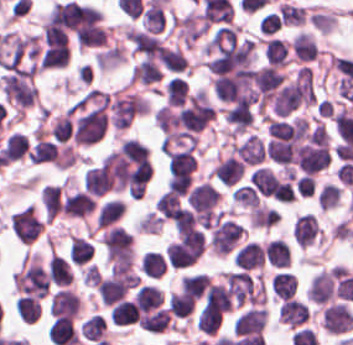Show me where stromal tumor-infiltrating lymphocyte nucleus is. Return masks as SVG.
Returning <instances> with one entry per match:
<instances>
[{
	"label": "stromal tumor-infiltrating lymphocyte nucleus",
	"instance_id": "stromal-tumor-infiltrating-lymphocyte-nucleus-1",
	"mask_svg": "<svg viewBox=\"0 0 353 345\" xmlns=\"http://www.w3.org/2000/svg\"><path fill=\"white\" fill-rule=\"evenodd\" d=\"M195 167L196 158L190 150H176L169 155V175L171 179L190 181Z\"/></svg>",
	"mask_w": 353,
	"mask_h": 345
},
{
	"label": "stromal tumor-infiltrating lymphocyte nucleus",
	"instance_id": "stromal-tumor-infiltrating-lymphocyte-nucleus-2",
	"mask_svg": "<svg viewBox=\"0 0 353 345\" xmlns=\"http://www.w3.org/2000/svg\"><path fill=\"white\" fill-rule=\"evenodd\" d=\"M48 335L53 345H75L78 340L68 316H55L48 328Z\"/></svg>",
	"mask_w": 353,
	"mask_h": 345
},
{
	"label": "stromal tumor-infiltrating lymphocyte nucleus",
	"instance_id": "stromal-tumor-infiltrating-lymphocyte-nucleus-3",
	"mask_svg": "<svg viewBox=\"0 0 353 345\" xmlns=\"http://www.w3.org/2000/svg\"><path fill=\"white\" fill-rule=\"evenodd\" d=\"M139 327L144 331L161 333L171 327V323L166 309H158L148 314H145L138 321Z\"/></svg>",
	"mask_w": 353,
	"mask_h": 345
},
{
	"label": "stromal tumor-infiltrating lymphocyte nucleus",
	"instance_id": "stromal-tumor-infiltrating-lymphocyte-nucleus-4",
	"mask_svg": "<svg viewBox=\"0 0 353 345\" xmlns=\"http://www.w3.org/2000/svg\"><path fill=\"white\" fill-rule=\"evenodd\" d=\"M55 158H57V145L38 138L27 153V160L36 164L51 161Z\"/></svg>",
	"mask_w": 353,
	"mask_h": 345
}]
</instances>
